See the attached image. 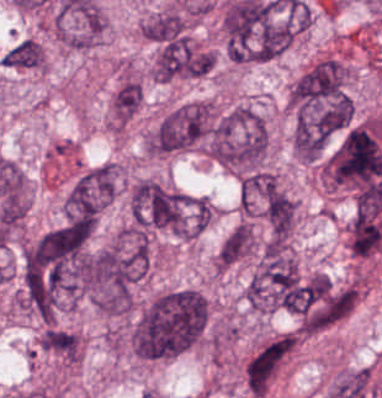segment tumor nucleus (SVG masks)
I'll return each instance as SVG.
<instances>
[{
	"mask_svg": "<svg viewBox=\"0 0 382 398\" xmlns=\"http://www.w3.org/2000/svg\"><path fill=\"white\" fill-rule=\"evenodd\" d=\"M207 311V297L195 288H169L156 295L142 313L140 350L144 358L157 360L183 352L204 332Z\"/></svg>",
	"mask_w": 382,
	"mask_h": 398,
	"instance_id": "1",
	"label": "tumor nucleus"
},
{
	"mask_svg": "<svg viewBox=\"0 0 382 398\" xmlns=\"http://www.w3.org/2000/svg\"><path fill=\"white\" fill-rule=\"evenodd\" d=\"M205 150L234 170L263 167L269 137L263 115L250 105H237L207 122Z\"/></svg>",
	"mask_w": 382,
	"mask_h": 398,
	"instance_id": "2",
	"label": "tumor nucleus"
},
{
	"mask_svg": "<svg viewBox=\"0 0 382 398\" xmlns=\"http://www.w3.org/2000/svg\"><path fill=\"white\" fill-rule=\"evenodd\" d=\"M217 112L210 99L180 102L144 132V148L154 153H171L197 145Z\"/></svg>",
	"mask_w": 382,
	"mask_h": 398,
	"instance_id": "3",
	"label": "tumor nucleus"
},
{
	"mask_svg": "<svg viewBox=\"0 0 382 398\" xmlns=\"http://www.w3.org/2000/svg\"><path fill=\"white\" fill-rule=\"evenodd\" d=\"M120 165L104 161L83 170L71 186L64 213L102 211L118 189Z\"/></svg>",
	"mask_w": 382,
	"mask_h": 398,
	"instance_id": "4",
	"label": "tumor nucleus"
},
{
	"mask_svg": "<svg viewBox=\"0 0 382 398\" xmlns=\"http://www.w3.org/2000/svg\"><path fill=\"white\" fill-rule=\"evenodd\" d=\"M295 345L291 333L278 335L260 345L245 360L242 373L248 397H261Z\"/></svg>",
	"mask_w": 382,
	"mask_h": 398,
	"instance_id": "5",
	"label": "tumor nucleus"
},
{
	"mask_svg": "<svg viewBox=\"0 0 382 398\" xmlns=\"http://www.w3.org/2000/svg\"><path fill=\"white\" fill-rule=\"evenodd\" d=\"M281 192L271 170L248 169L238 179V208L264 219Z\"/></svg>",
	"mask_w": 382,
	"mask_h": 398,
	"instance_id": "6",
	"label": "tumor nucleus"
},
{
	"mask_svg": "<svg viewBox=\"0 0 382 398\" xmlns=\"http://www.w3.org/2000/svg\"><path fill=\"white\" fill-rule=\"evenodd\" d=\"M262 213L270 239H287L294 228L297 203L286 192H266Z\"/></svg>",
	"mask_w": 382,
	"mask_h": 398,
	"instance_id": "7",
	"label": "tumor nucleus"
},
{
	"mask_svg": "<svg viewBox=\"0 0 382 398\" xmlns=\"http://www.w3.org/2000/svg\"><path fill=\"white\" fill-rule=\"evenodd\" d=\"M37 343L40 349L63 361L75 362L81 355L79 333L58 325H45Z\"/></svg>",
	"mask_w": 382,
	"mask_h": 398,
	"instance_id": "8",
	"label": "tumor nucleus"
},
{
	"mask_svg": "<svg viewBox=\"0 0 382 398\" xmlns=\"http://www.w3.org/2000/svg\"><path fill=\"white\" fill-rule=\"evenodd\" d=\"M254 245L253 226L248 221H241L221 242L216 257V271H224L252 252Z\"/></svg>",
	"mask_w": 382,
	"mask_h": 398,
	"instance_id": "9",
	"label": "tumor nucleus"
},
{
	"mask_svg": "<svg viewBox=\"0 0 382 398\" xmlns=\"http://www.w3.org/2000/svg\"><path fill=\"white\" fill-rule=\"evenodd\" d=\"M142 102V84L137 78L125 77L110 100V123L120 127L137 111Z\"/></svg>",
	"mask_w": 382,
	"mask_h": 398,
	"instance_id": "10",
	"label": "tumor nucleus"
},
{
	"mask_svg": "<svg viewBox=\"0 0 382 398\" xmlns=\"http://www.w3.org/2000/svg\"><path fill=\"white\" fill-rule=\"evenodd\" d=\"M8 68L41 69L42 46L31 37H24L0 59Z\"/></svg>",
	"mask_w": 382,
	"mask_h": 398,
	"instance_id": "11",
	"label": "tumor nucleus"
}]
</instances>
